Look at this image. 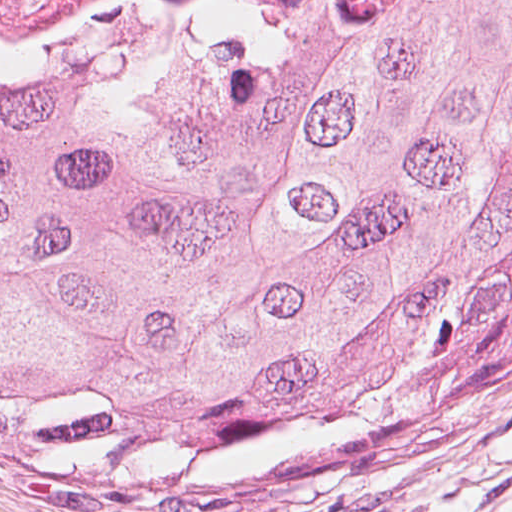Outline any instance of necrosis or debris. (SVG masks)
<instances>
[{
	"label": "necrosis or debris",
	"instance_id": "necrosis-or-debris-1",
	"mask_svg": "<svg viewBox=\"0 0 512 512\" xmlns=\"http://www.w3.org/2000/svg\"><path fill=\"white\" fill-rule=\"evenodd\" d=\"M236 4L237 0H0V43L33 41L70 29L164 14L211 12Z\"/></svg>",
	"mask_w": 512,
	"mask_h": 512
}]
</instances>
